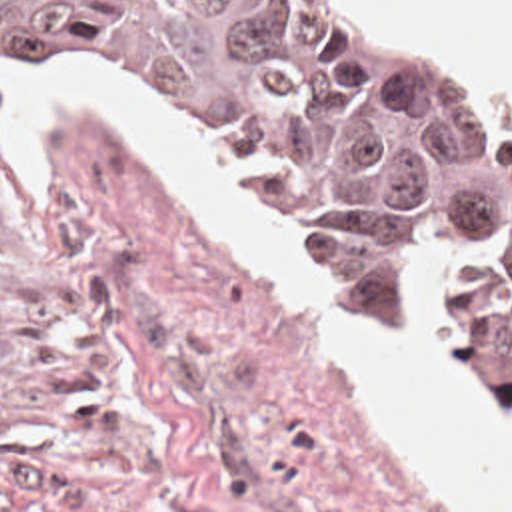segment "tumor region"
I'll return each mask as SVG.
<instances>
[{"label":"tumor region","mask_w":512,"mask_h":512,"mask_svg":"<svg viewBox=\"0 0 512 512\" xmlns=\"http://www.w3.org/2000/svg\"><path fill=\"white\" fill-rule=\"evenodd\" d=\"M0 69L130 79L264 193L324 197L336 277L376 323L426 267L448 343L512 425V145L436 47L374 43L304 0H0Z\"/></svg>","instance_id":"1"}]
</instances>
